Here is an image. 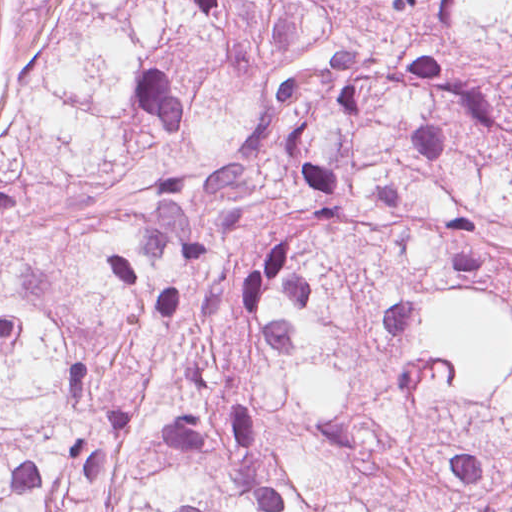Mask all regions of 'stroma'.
<instances>
[{"instance_id":"obj_1","label":"stroma","mask_w":512,"mask_h":512,"mask_svg":"<svg viewBox=\"0 0 512 512\" xmlns=\"http://www.w3.org/2000/svg\"><path fill=\"white\" fill-rule=\"evenodd\" d=\"M59 0H0V92L28 21L52 20ZM221 13L294 42L300 61L385 73L415 27L406 0H230Z\"/></svg>"}]
</instances>
